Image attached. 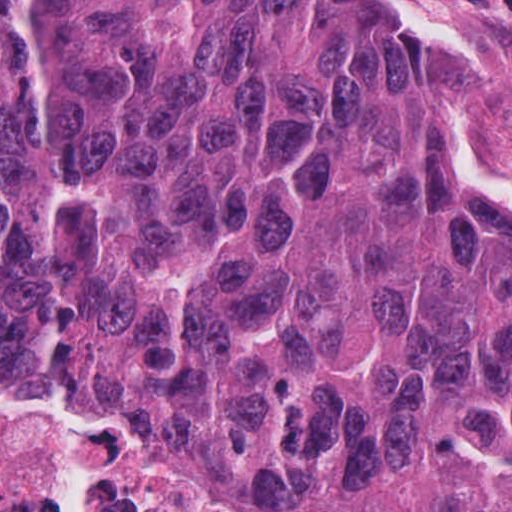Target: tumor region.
I'll use <instances>...</instances> for the list:
<instances>
[{"label":"tumor region","instance_id":"1","mask_svg":"<svg viewBox=\"0 0 512 512\" xmlns=\"http://www.w3.org/2000/svg\"><path fill=\"white\" fill-rule=\"evenodd\" d=\"M0 372L512 512V182L379 0H0Z\"/></svg>","mask_w":512,"mask_h":512}]
</instances>
